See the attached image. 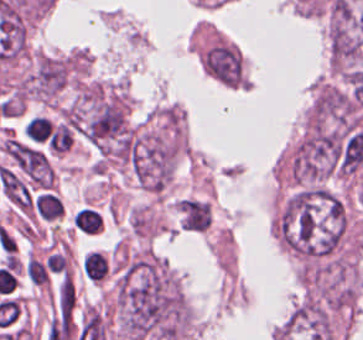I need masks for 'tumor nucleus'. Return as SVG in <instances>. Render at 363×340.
Instances as JSON below:
<instances>
[{"label": "tumor nucleus", "instance_id": "obj_1", "mask_svg": "<svg viewBox=\"0 0 363 340\" xmlns=\"http://www.w3.org/2000/svg\"><path fill=\"white\" fill-rule=\"evenodd\" d=\"M274 229L283 248L302 259L332 253L344 235L343 203L323 188H303L284 203Z\"/></svg>", "mask_w": 363, "mask_h": 340}, {"label": "tumor nucleus", "instance_id": "obj_2", "mask_svg": "<svg viewBox=\"0 0 363 340\" xmlns=\"http://www.w3.org/2000/svg\"><path fill=\"white\" fill-rule=\"evenodd\" d=\"M342 141L324 126L311 125L290 158L291 178L300 186L323 181L334 174Z\"/></svg>", "mask_w": 363, "mask_h": 340}, {"label": "tumor nucleus", "instance_id": "obj_3", "mask_svg": "<svg viewBox=\"0 0 363 340\" xmlns=\"http://www.w3.org/2000/svg\"><path fill=\"white\" fill-rule=\"evenodd\" d=\"M66 80L65 59L42 54L38 57L29 78V91L38 98L50 99Z\"/></svg>", "mask_w": 363, "mask_h": 340}]
</instances>
